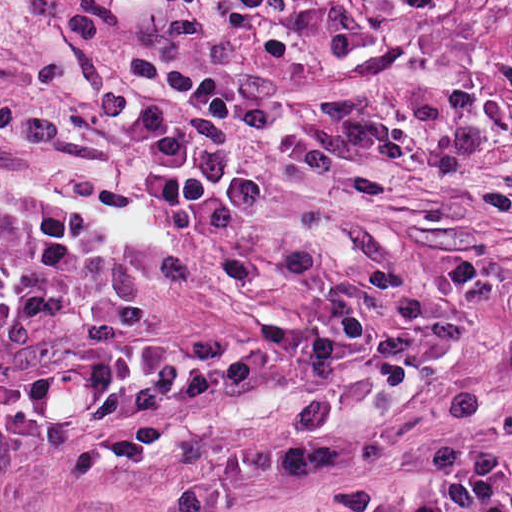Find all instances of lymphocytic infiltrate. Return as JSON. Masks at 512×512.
Here are the masks:
<instances>
[{
    "label": "lymphocytic infiltrate",
    "instance_id": "lymphocytic-infiltrate-1",
    "mask_svg": "<svg viewBox=\"0 0 512 512\" xmlns=\"http://www.w3.org/2000/svg\"><path fill=\"white\" fill-rule=\"evenodd\" d=\"M202 157V219L165 227L121 190H0V453L52 445L182 382L207 350L142 334L157 293L192 270L174 251L132 258L107 236L108 214L161 226L213 248L254 228L280 204L251 162L233 115L194 100ZM253 136V135H252ZM363 271L375 277L359 255ZM314 250L293 253L278 314L249 306L250 259L224 276L248 324L375 314L330 288L290 301L295 282L319 270ZM384 288V287H383Z\"/></svg>",
    "mask_w": 512,
    "mask_h": 512
}]
</instances>
